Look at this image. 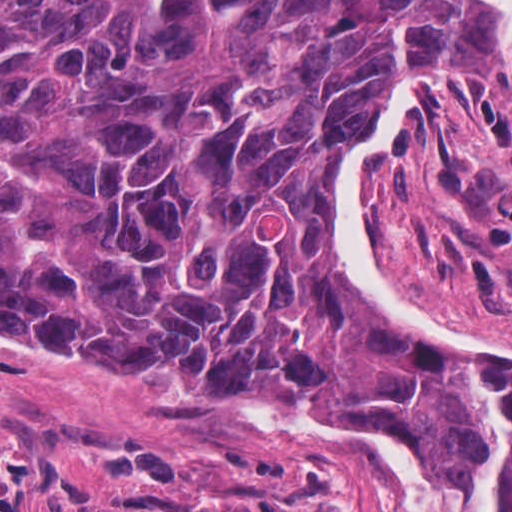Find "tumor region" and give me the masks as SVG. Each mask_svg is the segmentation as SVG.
I'll list each match as a JSON object with an SVG mask.
<instances>
[{"label":"tumor region","instance_id":"1","mask_svg":"<svg viewBox=\"0 0 512 512\" xmlns=\"http://www.w3.org/2000/svg\"><path fill=\"white\" fill-rule=\"evenodd\" d=\"M500 76L482 0H0V330L174 391L353 393L475 512L483 364L511 449L512 368L414 357L359 310L322 178L412 77L437 111ZM123 512H335L130 483Z\"/></svg>","mask_w":512,"mask_h":512}]
</instances>
